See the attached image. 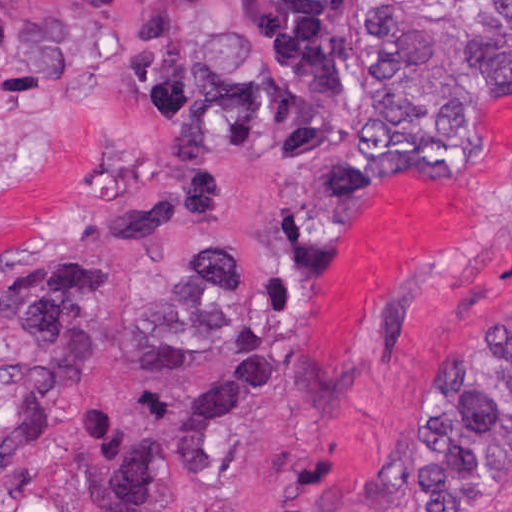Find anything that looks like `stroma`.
<instances>
[{"mask_svg":"<svg viewBox=\"0 0 512 512\" xmlns=\"http://www.w3.org/2000/svg\"><path fill=\"white\" fill-rule=\"evenodd\" d=\"M352 55L366 117L340 147L219 160L228 222L170 225L153 261L133 245L60 253L106 277L108 314L154 307L206 245H257L265 270L247 334L207 364L151 373L138 344L98 340L82 392L23 455L1 398V280L54 256L42 238L103 197L116 149L91 111L28 132L1 116L0 0V512H399L388 488L425 376L512 331V99L477 110L423 172L331 204L319 165L370 105L361 0ZM481 512H512V483Z\"/></svg>","mask_w":512,"mask_h":512,"instance_id":"1","label":"stroma"}]
</instances>
